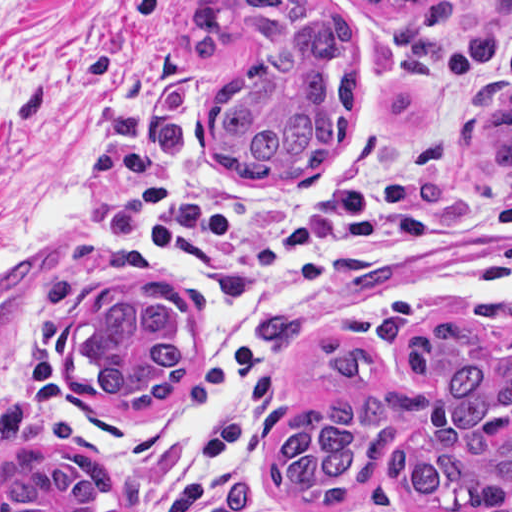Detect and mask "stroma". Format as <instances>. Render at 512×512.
Here are the masks:
<instances>
[{
    "label": "stroma",
    "mask_w": 512,
    "mask_h": 512,
    "mask_svg": "<svg viewBox=\"0 0 512 512\" xmlns=\"http://www.w3.org/2000/svg\"><path fill=\"white\" fill-rule=\"evenodd\" d=\"M198 0H0V405L29 411L48 451L75 449L109 475L106 512H130L159 491L174 465L180 413L220 347V325L192 280L159 259L137 232L146 202L194 184L283 197L303 181H245L220 172L208 119L226 78L256 55L254 32L220 60L186 34ZM349 26L360 45V108L346 144L383 148L456 111L482 62L512 32V0H454L449 61L438 75L409 72L395 32L361 0H313ZM492 197L512 194L498 175L458 151L445 179ZM154 286L187 305L190 365L158 409L110 401L78 360L86 313L99 296ZM492 304H462L384 328H323L288 365L276 397L267 459L289 425L317 403L346 393L322 351L335 331L366 342L390 376L428 391L404 338L438 317L465 320L483 354L507 340L484 319ZM408 437L387 447L380 469L355 496L296 512H401L396 479Z\"/></svg>",
    "instance_id": "35a3bbf8"
}]
</instances>
